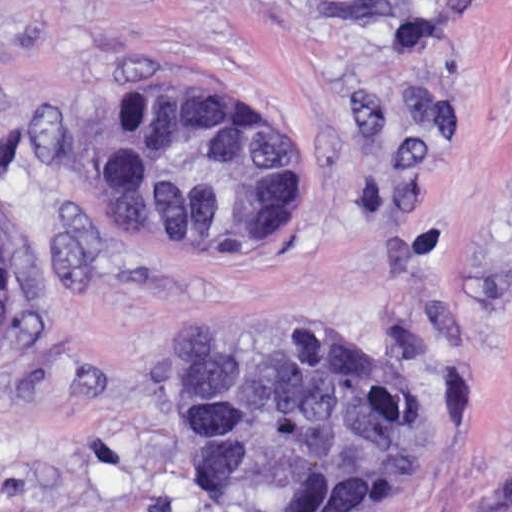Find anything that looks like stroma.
<instances>
[{
	"label": "stroma",
	"instance_id": "35a3bbf8",
	"mask_svg": "<svg viewBox=\"0 0 512 512\" xmlns=\"http://www.w3.org/2000/svg\"><path fill=\"white\" fill-rule=\"evenodd\" d=\"M132 90L268 108L311 185L138 245L88 179ZM0 512H512V0H0ZM391 373L386 475L342 507L211 482L174 429L189 332Z\"/></svg>",
	"mask_w": 512,
	"mask_h": 512
}]
</instances>
